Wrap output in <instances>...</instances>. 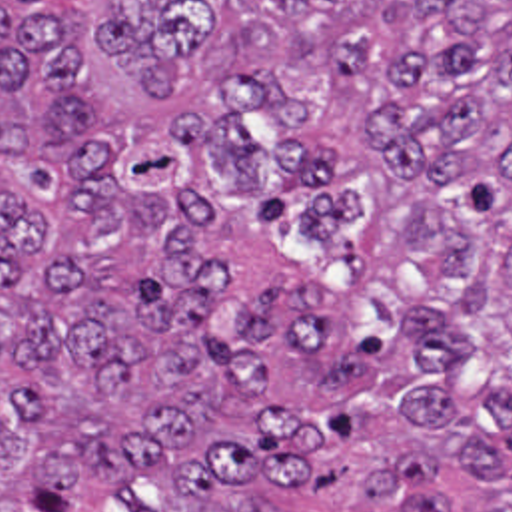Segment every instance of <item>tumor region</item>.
Instances as JSON below:
<instances>
[{
    "mask_svg": "<svg viewBox=\"0 0 512 512\" xmlns=\"http://www.w3.org/2000/svg\"><path fill=\"white\" fill-rule=\"evenodd\" d=\"M0 512H512V0H0Z\"/></svg>",
    "mask_w": 512,
    "mask_h": 512,
    "instance_id": "1",
    "label": "tumor region"
}]
</instances>
